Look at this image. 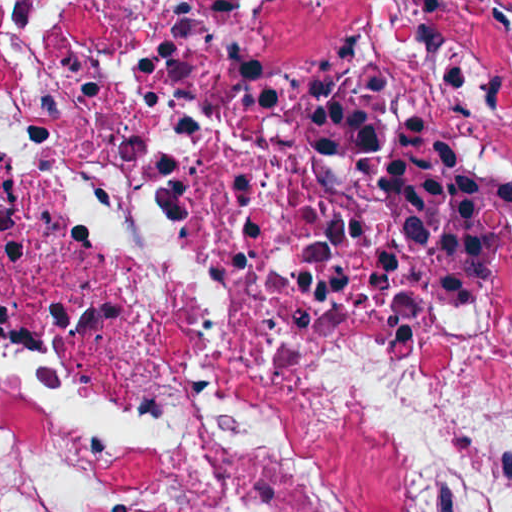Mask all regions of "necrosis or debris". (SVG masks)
<instances>
[{"mask_svg": "<svg viewBox=\"0 0 512 512\" xmlns=\"http://www.w3.org/2000/svg\"><path fill=\"white\" fill-rule=\"evenodd\" d=\"M0 512H512V1H0Z\"/></svg>", "mask_w": 512, "mask_h": 512, "instance_id": "obj_1", "label": "necrosis or debris"}]
</instances>
